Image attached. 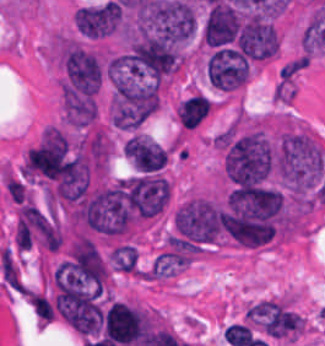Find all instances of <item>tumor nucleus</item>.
I'll return each mask as SVG.
<instances>
[{"label": "tumor nucleus", "mask_w": 325, "mask_h": 346, "mask_svg": "<svg viewBox=\"0 0 325 346\" xmlns=\"http://www.w3.org/2000/svg\"><path fill=\"white\" fill-rule=\"evenodd\" d=\"M122 155L128 165L139 173H159L166 167L171 147L139 130L127 134Z\"/></svg>", "instance_id": "obj_1"}, {"label": "tumor nucleus", "mask_w": 325, "mask_h": 346, "mask_svg": "<svg viewBox=\"0 0 325 346\" xmlns=\"http://www.w3.org/2000/svg\"><path fill=\"white\" fill-rule=\"evenodd\" d=\"M80 35L87 39H102L120 29V7L110 0L81 6L72 16Z\"/></svg>", "instance_id": "obj_2"}, {"label": "tumor nucleus", "mask_w": 325, "mask_h": 346, "mask_svg": "<svg viewBox=\"0 0 325 346\" xmlns=\"http://www.w3.org/2000/svg\"><path fill=\"white\" fill-rule=\"evenodd\" d=\"M250 71L246 57L228 46H221L208 56V81L221 89L241 87Z\"/></svg>", "instance_id": "obj_3"}, {"label": "tumor nucleus", "mask_w": 325, "mask_h": 346, "mask_svg": "<svg viewBox=\"0 0 325 346\" xmlns=\"http://www.w3.org/2000/svg\"><path fill=\"white\" fill-rule=\"evenodd\" d=\"M106 255L109 266L114 272L133 275L138 270L136 243L128 240H115Z\"/></svg>", "instance_id": "obj_4"}]
</instances>
